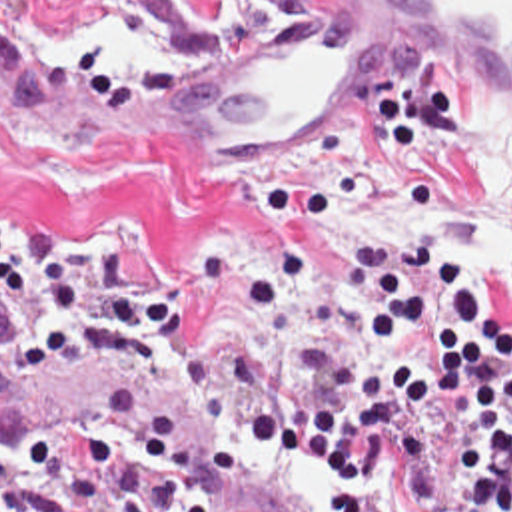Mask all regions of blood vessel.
Returning <instances> with one entry per match:
<instances>
[{
	"label": "blood vessel",
	"mask_w": 512,
	"mask_h": 512,
	"mask_svg": "<svg viewBox=\"0 0 512 512\" xmlns=\"http://www.w3.org/2000/svg\"><path fill=\"white\" fill-rule=\"evenodd\" d=\"M410 65L512 105V0H304L282 25L140 73H48L0 51V123L94 121L192 135L272 163L312 153L336 123L396 103ZM0 410L42 466L160 512H246L188 424L88 380L14 369Z\"/></svg>",
	"instance_id": "1"
}]
</instances>
